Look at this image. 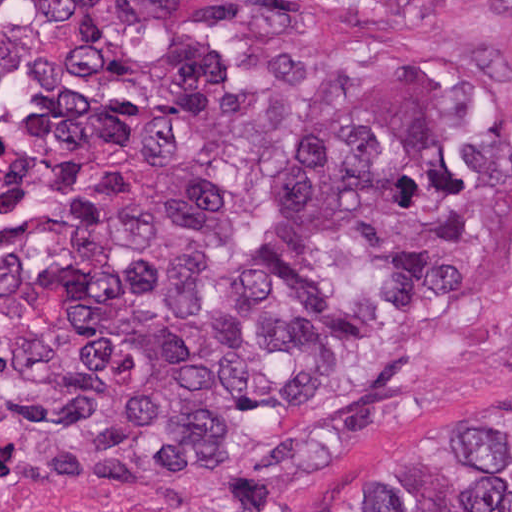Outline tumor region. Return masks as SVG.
Masks as SVG:
<instances>
[{"label":"tumor region","instance_id":"1","mask_svg":"<svg viewBox=\"0 0 512 512\" xmlns=\"http://www.w3.org/2000/svg\"><path fill=\"white\" fill-rule=\"evenodd\" d=\"M304 0H38L44 31L129 17L282 32ZM512 42V0L498 7ZM512 218V135L439 61L350 83L261 82L209 50L168 63L119 195L0 264V352L27 480L113 512L187 476H284L395 423L418 358L325 393L397 317L461 295ZM340 512H512V414L392 450Z\"/></svg>","mask_w":512,"mask_h":512}]
</instances>
